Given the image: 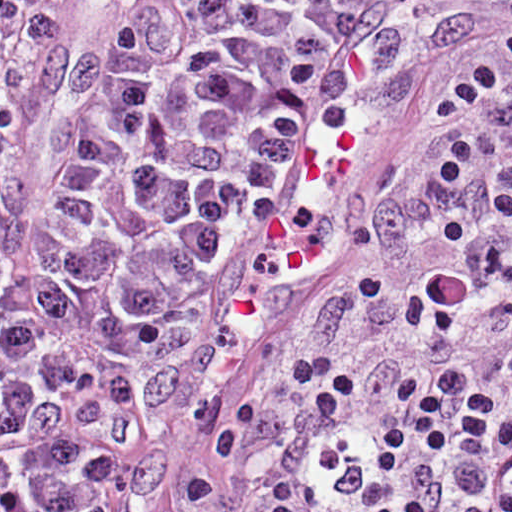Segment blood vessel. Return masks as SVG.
Returning <instances> with one entry per match:
<instances>
[{"mask_svg": "<svg viewBox=\"0 0 512 512\" xmlns=\"http://www.w3.org/2000/svg\"><path fill=\"white\" fill-rule=\"evenodd\" d=\"M420 94L403 36L379 18L343 10L303 110L254 185L207 293L220 283L310 275L347 235L367 165L414 115Z\"/></svg>", "mask_w": 512, "mask_h": 512, "instance_id": "8fb6f2fc", "label": "blood vessel"}]
</instances>
